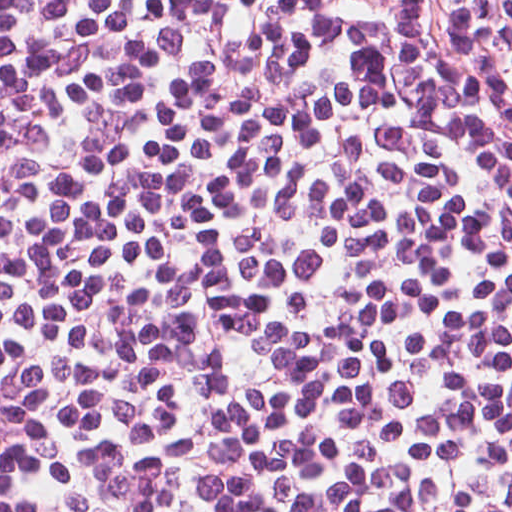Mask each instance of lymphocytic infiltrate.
Masks as SVG:
<instances>
[{
  "label": "lymphocytic infiltrate",
  "instance_id": "lymphocytic-infiltrate-1",
  "mask_svg": "<svg viewBox=\"0 0 512 512\" xmlns=\"http://www.w3.org/2000/svg\"><path fill=\"white\" fill-rule=\"evenodd\" d=\"M0 512H512V0H0Z\"/></svg>",
  "mask_w": 512,
  "mask_h": 512
}]
</instances>
